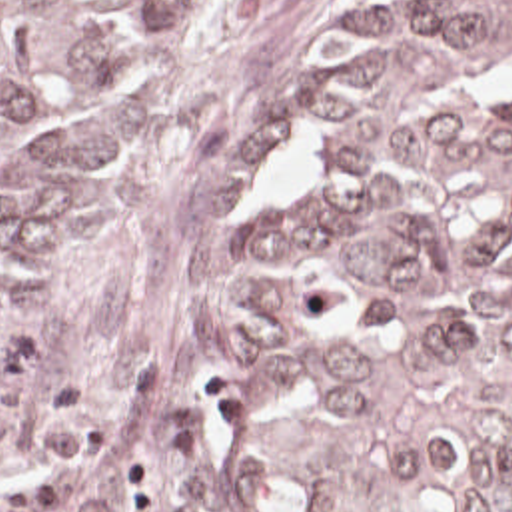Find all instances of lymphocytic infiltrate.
I'll list each match as a JSON object with an SVG mask.
<instances>
[{
  "instance_id": "obj_1",
  "label": "lymphocytic infiltrate",
  "mask_w": 512,
  "mask_h": 512,
  "mask_svg": "<svg viewBox=\"0 0 512 512\" xmlns=\"http://www.w3.org/2000/svg\"><path fill=\"white\" fill-rule=\"evenodd\" d=\"M37 432L25 454L65 480L73 512H163L167 470L153 452H139L119 462L115 486H101L87 472V460L101 444L99 430L77 426L79 402L69 380L55 378L33 396Z\"/></svg>"
}]
</instances>
